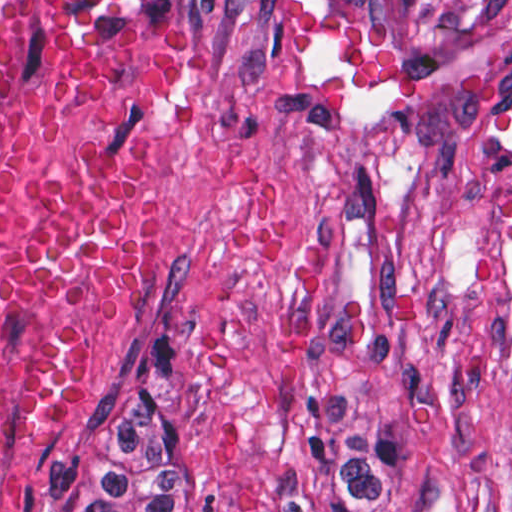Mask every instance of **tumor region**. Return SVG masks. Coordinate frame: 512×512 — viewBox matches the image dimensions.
<instances>
[{"instance_id":"e687c5a6","label":"tumor region","mask_w":512,"mask_h":512,"mask_svg":"<svg viewBox=\"0 0 512 512\" xmlns=\"http://www.w3.org/2000/svg\"><path fill=\"white\" fill-rule=\"evenodd\" d=\"M75 512H214L204 485L156 436L151 336L131 362L106 442L79 480Z\"/></svg>"}]
</instances>
